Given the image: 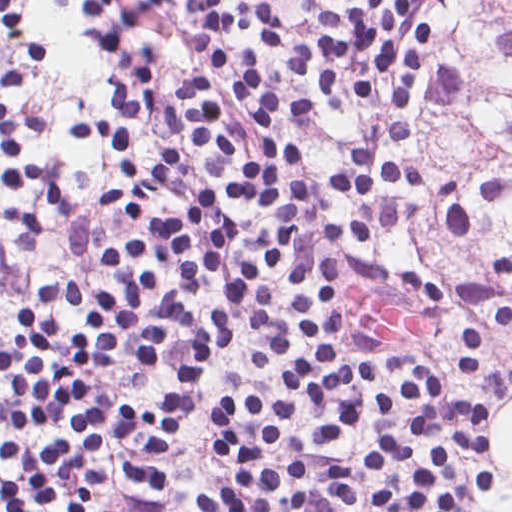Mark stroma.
Instances as JSON below:
<instances>
[{
    "label": "stroma",
    "instance_id": "obj_1",
    "mask_svg": "<svg viewBox=\"0 0 512 512\" xmlns=\"http://www.w3.org/2000/svg\"><path fill=\"white\" fill-rule=\"evenodd\" d=\"M224 9L233 0H222ZM267 25L260 30L231 32L216 39L227 53L249 45L265 63L266 83L272 95L283 99H308L316 107L277 111L281 134L290 142L312 151L318 176L348 165V154L356 148L386 146L384 126L392 120L413 124L411 135L385 153L392 160L421 163L441 180L462 182L474 198L485 180L500 177L509 194L502 203L470 207V226L465 235L453 234L444 224L437 206L418 190L389 185L377 197H335L316 193L309 217L299 227L290 246L270 261L261 279L273 292L283 321L296 334V347L280 353L267 375L246 369L248 356L270 352L255 339L250 319L230 316L236 337L207 366L203 384L189 416L179 427L170 446L158 456H149L145 441L129 440L107 432L104 450L94 454L92 465L109 478L96 495L99 512H201L197 497L229 478L213 461L211 450L219 443L211 423V410L240 390L288 392L286 376L290 365L303 353L297 335L296 311L290 301V268L303 254H329L364 259L384 267L406 268L440 285L444 303L432 302L414 292L368 280L340 278L342 310L346 330L376 344L372 353L377 364L382 354L397 350L417 356L444 372L454 391L463 396H484L492 402L486 421L490 451L488 469L492 488L474 501L472 512H495L512 497V476L498 456L502 423L512 416V399L498 394L467 369L451 351L453 326L458 318L462 294L438 267L394 239L434 237L446 241L454 260L456 282L461 291L464 265L475 255L503 242L512 234V167L457 166L436 152L428 134L433 87L448 59L453 27L448 0H427L403 23V43L414 31L433 25V40L411 109L398 110L394 102L398 72L382 82L371 98L360 100L353 92L349 72L341 77V89L329 105L318 100L319 69L304 76L293 59L320 40L322 29L311 10L300 1L267 6ZM88 6L74 0H21V11L32 30L49 42L47 63L14 51L0 24V101L16 115L37 113L41 122L35 132H21L17 140L24 159L47 165L58 181V200L0 182V348L7 334L17 330L9 315L13 304H28L45 318L65 323L73 332L80 315L39 305V294L55 278L65 277L79 285L112 286L104 263L106 240L120 233L146 229L129 214L104 212L99 204L103 192L123 177L119 160L106 151L78 144L67 124L79 114L106 107L108 97L98 81L102 67L112 61L96 50L84 23ZM144 41L155 43V68L160 77L181 80L192 67V50L187 48V23L171 10L133 39V57L142 52ZM223 46H222V44ZM167 148V127L161 119H150L137 137L141 172L161 159ZM139 185V177L127 183L117 200L122 211ZM422 204V219L381 226L352 242H336L320 234L324 223L352 224L364 204L399 199ZM353 288L370 294L414 319L428 321L426 332L417 337H379L356 328L348 319ZM168 326L167 353L147 368L135 366L128 358L129 340L108 353L106 364L90 379L94 390L103 394L115 416L122 396L150 394L169 388L186 354V339L175 321L177 315H146ZM379 378L366 390V399L381 388L403 384L406 374L378 365ZM290 424L305 451L275 453L271 460L307 462L311 470V494L305 512H334V493L323 470L333 462H344L359 449L369 447L382 436L413 426V411L394 419H370L348 434L333 450L321 449L314 438L313 419L299 403ZM80 430L57 427L49 431H22L0 419V448L11 435L32 443L74 437ZM265 458H269V455ZM16 465L0 453V475H10Z\"/></svg>",
    "mask_w": 512,
    "mask_h": 512
}]
</instances>
